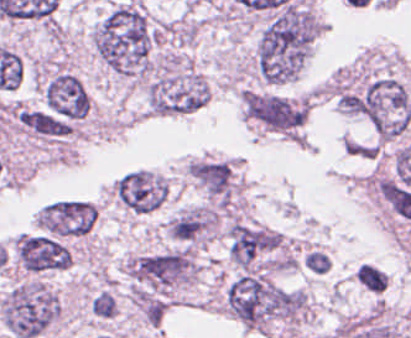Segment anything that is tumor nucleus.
I'll return each instance as SVG.
<instances>
[{"label": "tumor nucleus", "instance_id": "tumor-nucleus-1", "mask_svg": "<svg viewBox=\"0 0 411 338\" xmlns=\"http://www.w3.org/2000/svg\"><path fill=\"white\" fill-rule=\"evenodd\" d=\"M159 32L137 2L125 0L109 10L94 29L91 44L113 72L147 79L153 72Z\"/></svg>", "mask_w": 411, "mask_h": 338}, {"label": "tumor nucleus", "instance_id": "tumor-nucleus-2", "mask_svg": "<svg viewBox=\"0 0 411 338\" xmlns=\"http://www.w3.org/2000/svg\"><path fill=\"white\" fill-rule=\"evenodd\" d=\"M223 305L252 329L300 323L313 315L307 293L259 270L240 272L230 280L223 291Z\"/></svg>", "mask_w": 411, "mask_h": 338}, {"label": "tumor nucleus", "instance_id": "tumor-nucleus-3", "mask_svg": "<svg viewBox=\"0 0 411 338\" xmlns=\"http://www.w3.org/2000/svg\"><path fill=\"white\" fill-rule=\"evenodd\" d=\"M316 26L310 16H278L261 31L255 53L258 79L286 85L298 81L313 53Z\"/></svg>", "mask_w": 411, "mask_h": 338}, {"label": "tumor nucleus", "instance_id": "tumor-nucleus-4", "mask_svg": "<svg viewBox=\"0 0 411 338\" xmlns=\"http://www.w3.org/2000/svg\"><path fill=\"white\" fill-rule=\"evenodd\" d=\"M59 313L56 293L35 280L14 283L1 302L3 326L13 338L44 333Z\"/></svg>", "mask_w": 411, "mask_h": 338}, {"label": "tumor nucleus", "instance_id": "tumor-nucleus-5", "mask_svg": "<svg viewBox=\"0 0 411 338\" xmlns=\"http://www.w3.org/2000/svg\"><path fill=\"white\" fill-rule=\"evenodd\" d=\"M209 92L193 68H161L144 84L146 110L154 116L190 115L205 104Z\"/></svg>", "mask_w": 411, "mask_h": 338}, {"label": "tumor nucleus", "instance_id": "tumor-nucleus-6", "mask_svg": "<svg viewBox=\"0 0 411 338\" xmlns=\"http://www.w3.org/2000/svg\"><path fill=\"white\" fill-rule=\"evenodd\" d=\"M356 110L384 136H400L411 125V98L403 81L385 75L365 84Z\"/></svg>", "mask_w": 411, "mask_h": 338}, {"label": "tumor nucleus", "instance_id": "tumor-nucleus-7", "mask_svg": "<svg viewBox=\"0 0 411 338\" xmlns=\"http://www.w3.org/2000/svg\"><path fill=\"white\" fill-rule=\"evenodd\" d=\"M312 95L244 89L246 112L271 131L299 136L309 113Z\"/></svg>", "mask_w": 411, "mask_h": 338}, {"label": "tumor nucleus", "instance_id": "tumor-nucleus-8", "mask_svg": "<svg viewBox=\"0 0 411 338\" xmlns=\"http://www.w3.org/2000/svg\"><path fill=\"white\" fill-rule=\"evenodd\" d=\"M229 258L239 271L274 265L281 248L279 233L234 222L227 230Z\"/></svg>", "mask_w": 411, "mask_h": 338}, {"label": "tumor nucleus", "instance_id": "tumor-nucleus-9", "mask_svg": "<svg viewBox=\"0 0 411 338\" xmlns=\"http://www.w3.org/2000/svg\"><path fill=\"white\" fill-rule=\"evenodd\" d=\"M43 234L61 239H78L97 220L95 205L86 200L60 199L45 204L34 218Z\"/></svg>", "mask_w": 411, "mask_h": 338}, {"label": "tumor nucleus", "instance_id": "tumor-nucleus-10", "mask_svg": "<svg viewBox=\"0 0 411 338\" xmlns=\"http://www.w3.org/2000/svg\"><path fill=\"white\" fill-rule=\"evenodd\" d=\"M168 184L148 169H134L113 182L112 195L134 215L154 211L167 195Z\"/></svg>", "mask_w": 411, "mask_h": 338}, {"label": "tumor nucleus", "instance_id": "tumor-nucleus-11", "mask_svg": "<svg viewBox=\"0 0 411 338\" xmlns=\"http://www.w3.org/2000/svg\"><path fill=\"white\" fill-rule=\"evenodd\" d=\"M13 250L17 266L29 273H51L69 268V251L59 239L22 234L14 239Z\"/></svg>", "mask_w": 411, "mask_h": 338}]
</instances>
